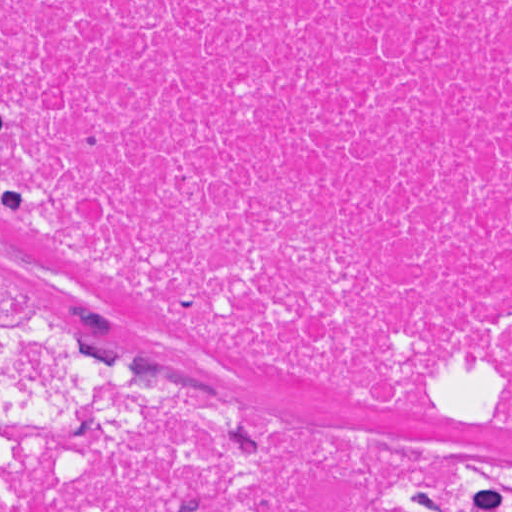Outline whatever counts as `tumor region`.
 Masks as SVG:
<instances>
[{
  "label": "tumor region",
  "mask_w": 512,
  "mask_h": 512,
  "mask_svg": "<svg viewBox=\"0 0 512 512\" xmlns=\"http://www.w3.org/2000/svg\"><path fill=\"white\" fill-rule=\"evenodd\" d=\"M487 509L512 512V467H497L487 490Z\"/></svg>",
  "instance_id": "e687c5a6"
}]
</instances>
